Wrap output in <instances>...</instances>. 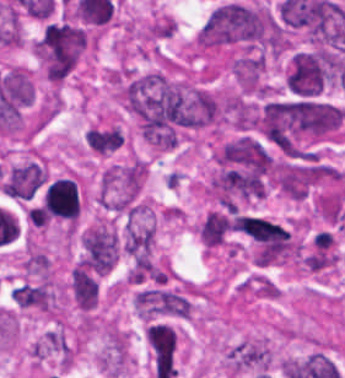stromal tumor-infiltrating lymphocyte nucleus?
<instances>
[{
    "instance_id": "1",
    "label": "stromal tumor-infiltrating lymphocyte nucleus",
    "mask_w": 345,
    "mask_h": 378,
    "mask_svg": "<svg viewBox=\"0 0 345 378\" xmlns=\"http://www.w3.org/2000/svg\"><path fill=\"white\" fill-rule=\"evenodd\" d=\"M26 217L33 224V226H38V227L46 226L38 206H35V205L31 206L29 210L27 211Z\"/></svg>"
}]
</instances>
